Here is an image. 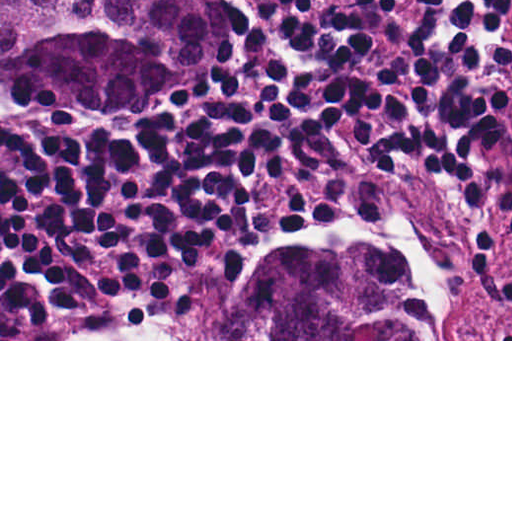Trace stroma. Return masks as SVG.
I'll use <instances>...</instances> for the list:
<instances>
[{
    "mask_svg": "<svg viewBox=\"0 0 512 512\" xmlns=\"http://www.w3.org/2000/svg\"><path fill=\"white\" fill-rule=\"evenodd\" d=\"M218 32V72L168 96H145L110 108L44 111H128L157 115L213 94L234 71V37L213 0H195ZM1 105L37 109L1 81L0 0V341H512V239L497 213L499 241L474 246L462 192L419 165L393 171L382 162L353 156L346 171H314L281 165L258 185V207L275 235L254 238L239 268L212 274L155 315H122L74 339H1ZM364 189L366 206L342 210L343 224L285 232L289 206L303 195ZM308 247H380L390 251L421 291L425 318L442 339H174L194 296L219 287L232 302H245L251 283L280 258Z\"/></svg>",
    "mask_w": 512,
    "mask_h": 512,
    "instance_id": "35a3bbf8",
    "label": "stroma"
}]
</instances>
